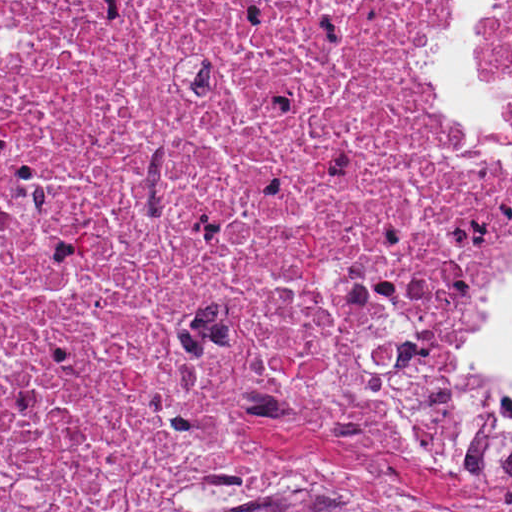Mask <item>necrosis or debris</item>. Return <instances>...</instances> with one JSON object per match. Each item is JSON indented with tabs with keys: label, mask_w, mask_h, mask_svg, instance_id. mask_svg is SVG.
<instances>
[{
	"label": "necrosis or debris",
	"mask_w": 512,
	"mask_h": 512,
	"mask_svg": "<svg viewBox=\"0 0 512 512\" xmlns=\"http://www.w3.org/2000/svg\"><path fill=\"white\" fill-rule=\"evenodd\" d=\"M427 41L450 0H1V512H347L382 453L512 488L466 356L512 163Z\"/></svg>",
	"instance_id": "necrosis-or-debris-1"
}]
</instances>
